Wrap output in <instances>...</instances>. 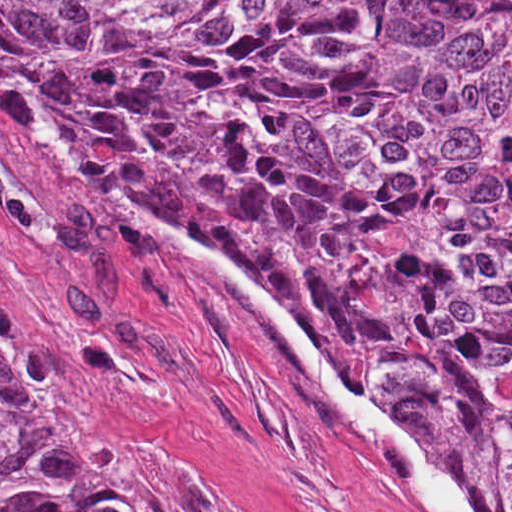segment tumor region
<instances>
[{"instance_id":"1","label":"tumor region","mask_w":512,"mask_h":512,"mask_svg":"<svg viewBox=\"0 0 512 512\" xmlns=\"http://www.w3.org/2000/svg\"><path fill=\"white\" fill-rule=\"evenodd\" d=\"M0 71L512 512V1H0ZM0 512H158L30 407L1 320Z\"/></svg>"}]
</instances>
